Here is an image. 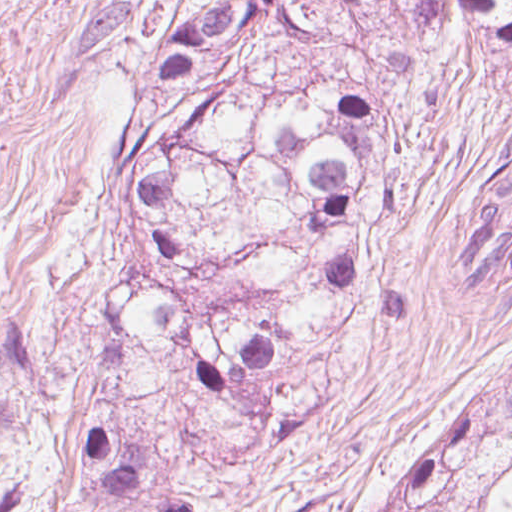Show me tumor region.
<instances>
[{"label":"tumor region","instance_id":"obj_1","mask_svg":"<svg viewBox=\"0 0 512 512\" xmlns=\"http://www.w3.org/2000/svg\"><path fill=\"white\" fill-rule=\"evenodd\" d=\"M512 40V0H156L91 197L113 266L88 336L87 512H213L296 416L390 208L400 112ZM456 240L512 288V131ZM370 512H512V352Z\"/></svg>","mask_w":512,"mask_h":512}]
</instances>
